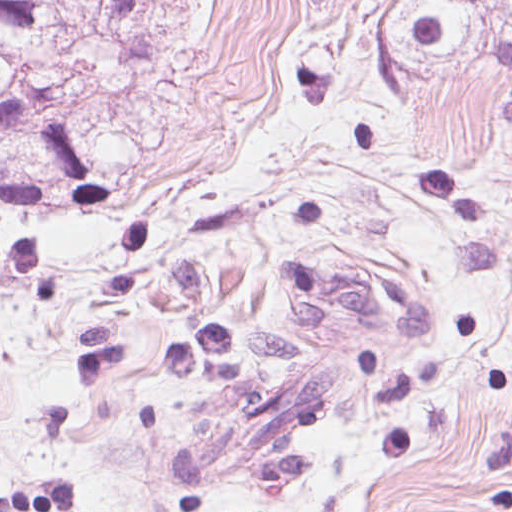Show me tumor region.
Masks as SVG:
<instances>
[{
	"instance_id": "e687c5a6",
	"label": "tumor region",
	"mask_w": 512,
	"mask_h": 512,
	"mask_svg": "<svg viewBox=\"0 0 512 512\" xmlns=\"http://www.w3.org/2000/svg\"><path fill=\"white\" fill-rule=\"evenodd\" d=\"M373 68L389 109L414 128L455 81L482 91L512 134V0H391Z\"/></svg>"
}]
</instances>
